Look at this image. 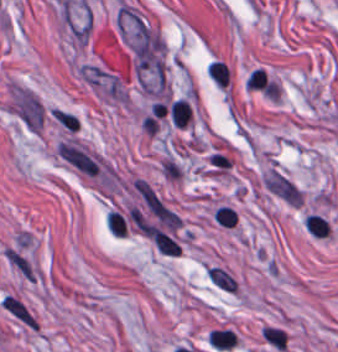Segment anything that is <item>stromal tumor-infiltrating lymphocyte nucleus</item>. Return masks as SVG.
Masks as SVG:
<instances>
[{
    "instance_id": "obj_7",
    "label": "stromal tumor-infiltrating lymphocyte nucleus",
    "mask_w": 338,
    "mask_h": 352,
    "mask_svg": "<svg viewBox=\"0 0 338 352\" xmlns=\"http://www.w3.org/2000/svg\"><path fill=\"white\" fill-rule=\"evenodd\" d=\"M207 74L220 85H224L227 80L228 67L219 59H212Z\"/></svg>"
},
{
    "instance_id": "obj_6",
    "label": "stromal tumor-infiltrating lymphocyte nucleus",
    "mask_w": 338,
    "mask_h": 352,
    "mask_svg": "<svg viewBox=\"0 0 338 352\" xmlns=\"http://www.w3.org/2000/svg\"><path fill=\"white\" fill-rule=\"evenodd\" d=\"M304 226L307 232L317 236L327 235V219L320 214L308 213L306 214Z\"/></svg>"
},
{
    "instance_id": "obj_1",
    "label": "stromal tumor-infiltrating lymphocyte nucleus",
    "mask_w": 338,
    "mask_h": 352,
    "mask_svg": "<svg viewBox=\"0 0 338 352\" xmlns=\"http://www.w3.org/2000/svg\"><path fill=\"white\" fill-rule=\"evenodd\" d=\"M208 219L217 228H237L240 212L228 198H214L207 207Z\"/></svg>"
},
{
    "instance_id": "obj_5",
    "label": "stromal tumor-infiltrating lymphocyte nucleus",
    "mask_w": 338,
    "mask_h": 352,
    "mask_svg": "<svg viewBox=\"0 0 338 352\" xmlns=\"http://www.w3.org/2000/svg\"><path fill=\"white\" fill-rule=\"evenodd\" d=\"M191 108L186 99H172L169 108V118L176 126H184L190 117Z\"/></svg>"
},
{
    "instance_id": "obj_2",
    "label": "stromal tumor-infiltrating lymphocyte nucleus",
    "mask_w": 338,
    "mask_h": 352,
    "mask_svg": "<svg viewBox=\"0 0 338 352\" xmlns=\"http://www.w3.org/2000/svg\"><path fill=\"white\" fill-rule=\"evenodd\" d=\"M259 336L260 341L277 352L285 348V330L276 322H263L259 329Z\"/></svg>"
},
{
    "instance_id": "obj_4",
    "label": "stromal tumor-infiltrating lymphocyte nucleus",
    "mask_w": 338,
    "mask_h": 352,
    "mask_svg": "<svg viewBox=\"0 0 338 352\" xmlns=\"http://www.w3.org/2000/svg\"><path fill=\"white\" fill-rule=\"evenodd\" d=\"M208 339L213 346L230 348L237 341V333L232 327H212Z\"/></svg>"
},
{
    "instance_id": "obj_3",
    "label": "stromal tumor-infiltrating lymphocyte nucleus",
    "mask_w": 338,
    "mask_h": 352,
    "mask_svg": "<svg viewBox=\"0 0 338 352\" xmlns=\"http://www.w3.org/2000/svg\"><path fill=\"white\" fill-rule=\"evenodd\" d=\"M151 238L161 253L169 255H178L181 253L180 243L171 235L156 228L151 232Z\"/></svg>"
}]
</instances>
